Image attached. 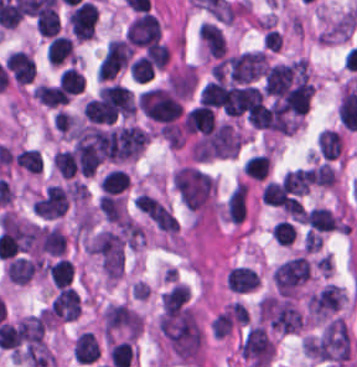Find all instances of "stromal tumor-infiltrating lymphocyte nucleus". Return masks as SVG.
I'll list each match as a JSON object with an SVG mask.
<instances>
[{
  "mask_svg": "<svg viewBox=\"0 0 357 367\" xmlns=\"http://www.w3.org/2000/svg\"><path fill=\"white\" fill-rule=\"evenodd\" d=\"M137 104L144 116L157 123H171L179 112V103L166 89L151 87L139 93Z\"/></svg>",
  "mask_w": 357,
  "mask_h": 367,
  "instance_id": "stromal-tumor-infiltrating-lymphocyte-nucleus-1",
  "label": "stromal tumor-infiltrating lymphocyte nucleus"
},
{
  "mask_svg": "<svg viewBox=\"0 0 357 367\" xmlns=\"http://www.w3.org/2000/svg\"><path fill=\"white\" fill-rule=\"evenodd\" d=\"M98 10L90 0H83L70 12L69 26L73 35L79 38H87L93 35Z\"/></svg>",
  "mask_w": 357,
  "mask_h": 367,
  "instance_id": "stromal-tumor-infiltrating-lymphocyte-nucleus-2",
  "label": "stromal tumor-infiltrating lymphocyte nucleus"
},
{
  "mask_svg": "<svg viewBox=\"0 0 357 367\" xmlns=\"http://www.w3.org/2000/svg\"><path fill=\"white\" fill-rule=\"evenodd\" d=\"M182 123L187 132H205L215 123L214 112L200 103L185 111Z\"/></svg>",
  "mask_w": 357,
  "mask_h": 367,
  "instance_id": "stromal-tumor-infiltrating-lymphocyte-nucleus-3",
  "label": "stromal tumor-infiltrating lymphocyte nucleus"
},
{
  "mask_svg": "<svg viewBox=\"0 0 357 367\" xmlns=\"http://www.w3.org/2000/svg\"><path fill=\"white\" fill-rule=\"evenodd\" d=\"M72 353L79 362H93L99 354V346L93 332L82 330L75 337Z\"/></svg>",
  "mask_w": 357,
  "mask_h": 367,
  "instance_id": "stromal-tumor-infiltrating-lymphocyte-nucleus-4",
  "label": "stromal tumor-infiltrating lymphocyte nucleus"
},
{
  "mask_svg": "<svg viewBox=\"0 0 357 367\" xmlns=\"http://www.w3.org/2000/svg\"><path fill=\"white\" fill-rule=\"evenodd\" d=\"M73 55L70 37L52 36L46 46L45 58L49 64L60 65L70 61Z\"/></svg>",
  "mask_w": 357,
  "mask_h": 367,
  "instance_id": "stromal-tumor-infiltrating-lymphocyte-nucleus-5",
  "label": "stromal tumor-infiltrating lymphocyte nucleus"
},
{
  "mask_svg": "<svg viewBox=\"0 0 357 367\" xmlns=\"http://www.w3.org/2000/svg\"><path fill=\"white\" fill-rule=\"evenodd\" d=\"M129 185L126 171L110 169L100 180L99 187L102 192L120 193Z\"/></svg>",
  "mask_w": 357,
  "mask_h": 367,
  "instance_id": "stromal-tumor-infiltrating-lymphocyte-nucleus-6",
  "label": "stromal tumor-infiltrating lymphocyte nucleus"
},
{
  "mask_svg": "<svg viewBox=\"0 0 357 367\" xmlns=\"http://www.w3.org/2000/svg\"><path fill=\"white\" fill-rule=\"evenodd\" d=\"M270 160L265 154H252L242 165L243 171L255 180H263L269 171Z\"/></svg>",
  "mask_w": 357,
  "mask_h": 367,
  "instance_id": "stromal-tumor-infiltrating-lymphocyte-nucleus-7",
  "label": "stromal tumor-infiltrating lymphocyte nucleus"
},
{
  "mask_svg": "<svg viewBox=\"0 0 357 367\" xmlns=\"http://www.w3.org/2000/svg\"><path fill=\"white\" fill-rule=\"evenodd\" d=\"M47 271L53 281L58 287L68 284L73 269L68 258H59L49 262Z\"/></svg>",
  "mask_w": 357,
  "mask_h": 367,
  "instance_id": "stromal-tumor-infiltrating-lymphocyte-nucleus-8",
  "label": "stromal tumor-infiltrating lymphocyte nucleus"
},
{
  "mask_svg": "<svg viewBox=\"0 0 357 367\" xmlns=\"http://www.w3.org/2000/svg\"><path fill=\"white\" fill-rule=\"evenodd\" d=\"M83 74L74 66H67L58 78V85L66 92L77 93L83 84Z\"/></svg>",
  "mask_w": 357,
  "mask_h": 367,
  "instance_id": "stromal-tumor-infiltrating-lymphocyte-nucleus-9",
  "label": "stromal tumor-infiltrating lymphocyte nucleus"
}]
</instances>
